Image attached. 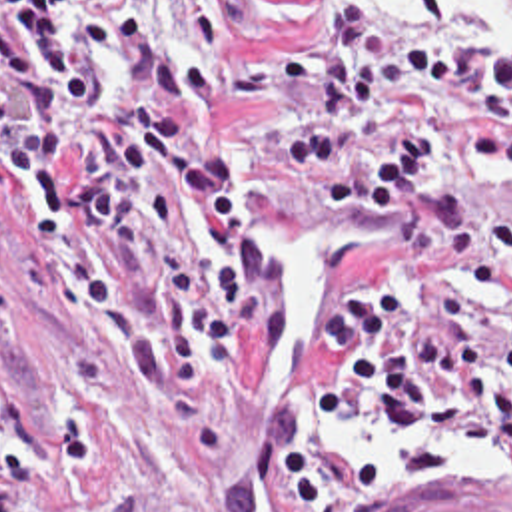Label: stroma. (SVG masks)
<instances>
[{"mask_svg": "<svg viewBox=\"0 0 512 512\" xmlns=\"http://www.w3.org/2000/svg\"><path fill=\"white\" fill-rule=\"evenodd\" d=\"M441 7L475 41H489L451 1ZM336 11L350 9L336 0H256L218 55L202 53L186 15L158 19L160 35L226 75L224 109L200 117L228 137L242 206L268 230L292 276V352L268 360L242 336L232 374L218 380L234 406V466L204 462L184 424L100 356L86 310L56 318L28 302L20 189L10 185L0 222V512H280L252 448L262 426L300 448L330 512H402L459 488L512 494L509 436L495 456L451 450L443 474H398L380 428L324 426L318 416L322 312L358 268L402 248L380 228L304 202L280 149V135L310 103L318 49ZM354 21L420 51L441 37L422 15L408 33ZM12 107L18 93L0 85V109ZM451 185L512 206V173H481L457 157ZM503 500L512 510V498Z\"/></svg>", "mask_w": 512, "mask_h": 512, "instance_id": "stroma-1", "label": "stroma"}]
</instances>
